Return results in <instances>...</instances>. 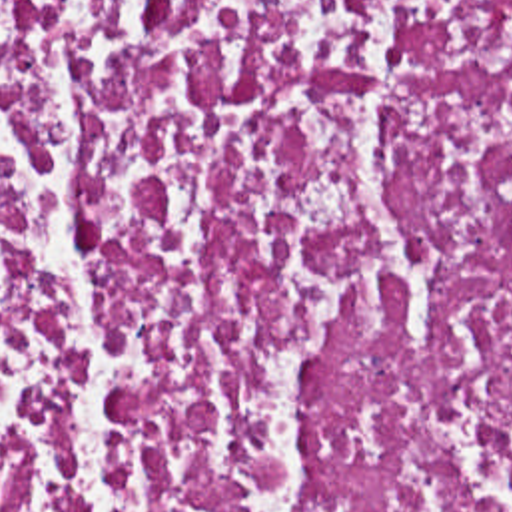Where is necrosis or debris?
Wrapping results in <instances>:
<instances>
[{"instance_id":"obj_1","label":"necrosis or debris","mask_w":512,"mask_h":512,"mask_svg":"<svg viewBox=\"0 0 512 512\" xmlns=\"http://www.w3.org/2000/svg\"><path fill=\"white\" fill-rule=\"evenodd\" d=\"M0 512H512V0H0Z\"/></svg>"}]
</instances>
